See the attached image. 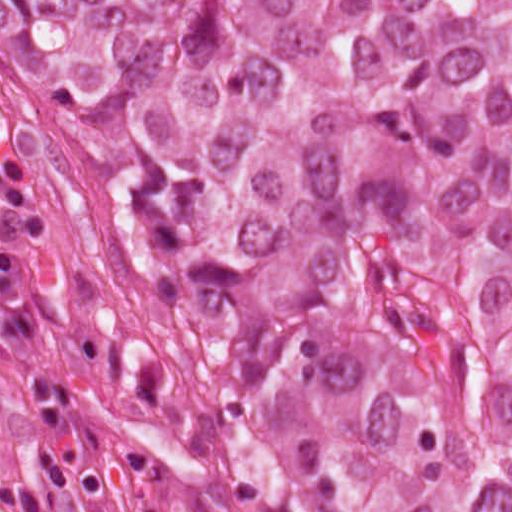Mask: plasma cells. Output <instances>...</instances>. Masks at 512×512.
Segmentation results:
<instances>
[{
  "mask_svg": "<svg viewBox=\"0 0 512 512\" xmlns=\"http://www.w3.org/2000/svg\"><path fill=\"white\" fill-rule=\"evenodd\" d=\"M37 325L38 316L26 301L18 252H0V335H28ZM71 393V384L53 375L30 382L35 457L25 480L0 484L1 512H43L51 487L80 495L101 493L98 472L70 462L56 444Z\"/></svg>",
  "mask_w": 512,
  "mask_h": 512,
  "instance_id": "obj_1",
  "label": "plasma cells"
}]
</instances>
